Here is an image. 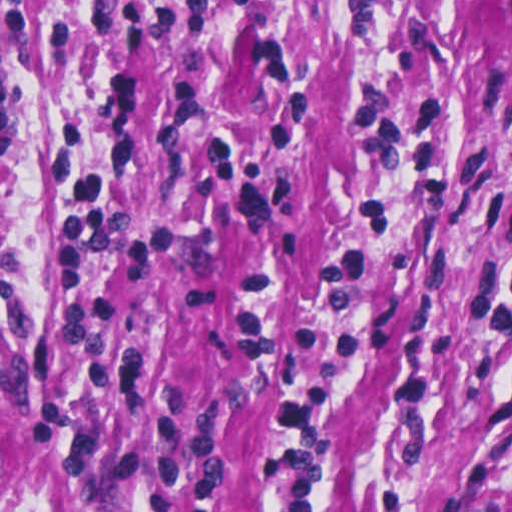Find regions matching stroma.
Segmentation results:
<instances>
[{"instance_id": "obj_1", "label": "stroma", "mask_w": 512, "mask_h": 512, "mask_svg": "<svg viewBox=\"0 0 512 512\" xmlns=\"http://www.w3.org/2000/svg\"><path fill=\"white\" fill-rule=\"evenodd\" d=\"M458 105L453 182L390 200L327 512H512V353L461 299L512 240V0H0V512H258L279 386L236 318L324 313L375 160L354 86Z\"/></svg>"}]
</instances>
